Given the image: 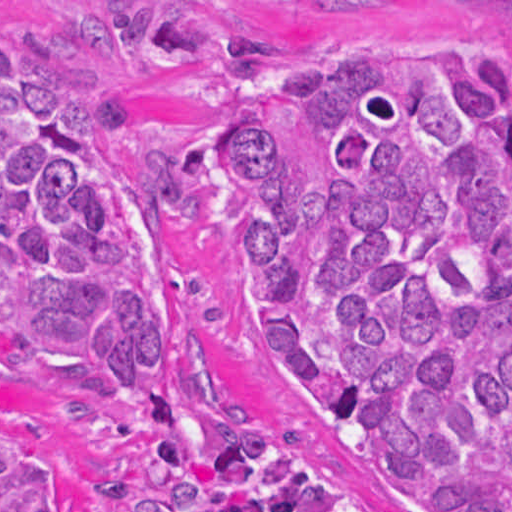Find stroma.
Masks as SVG:
<instances>
[{"label":"stroma","instance_id":"stroma-1","mask_svg":"<svg viewBox=\"0 0 512 512\" xmlns=\"http://www.w3.org/2000/svg\"><path fill=\"white\" fill-rule=\"evenodd\" d=\"M0 36L26 51L66 43L93 60L87 107L114 99L140 149L113 181L126 209L123 263L153 293H182L171 358L195 409L262 427H307L259 348V216L216 143L240 106L216 59L236 39L281 59H332L446 39L512 57V0H0ZM82 367L0 327V434L45 469L56 512H161L147 430L84 418Z\"/></svg>","mask_w":512,"mask_h":512}]
</instances>
